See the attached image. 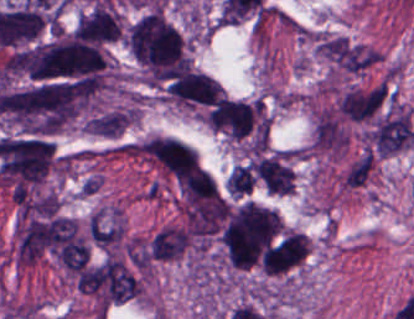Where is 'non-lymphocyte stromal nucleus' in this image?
Here are the masks:
<instances>
[{
    "instance_id": "obj_1",
    "label": "non-lymphocyte stromal nucleus",
    "mask_w": 414,
    "mask_h": 319,
    "mask_svg": "<svg viewBox=\"0 0 414 319\" xmlns=\"http://www.w3.org/2000/svg\"><path fill=\"white\" fill-rule=\"evenodd\" d=\"M391 100L387 82L355 87L340 95L337 111L344 121H369Z\"/></svg>"
},
{
    "instance_id": "obj_5",
    "label": "non-lymphocyte stromal nucleus",
    "mask_w": 414,
    "mask_h": 319,
    "mask_svg": "<svg viewBox=\"0 0 414 319\" xmlns=\"http://www.w3.org/2000/svg\"><path fill=\"white\" fill-rule=\"evenodd\" d=\"M133 118L129 107L103 111L85 123V132L98 137H118L124 132Z\"/></svg>"
},
{
    "instance_id": "obj_2",
    "label": "non-lymphocyte stromal nucleus",
    "mask_w": 414,
    "mask_h": 319,
    "mask_svg": "<svg viewBox=\"0 0 414 319\" xmlns=\"http://www.w3.org/2000/svg\"><path fill=\"white\" fill-rule=\"evenodd\" d=\"M367 135L382 155L396 153L414 142L411 121L404 111L377 120Z\"/></svg>"
},
{
    "instance_id": "obj_6",
    "label": "non-lymphocyte stromal nucleus",
    "mask_w": 414,
    "mask_h": 319,
    "mask_svg": "<svg viewBox=\"0 0 414 319\" xmlns=\"http://www.w3.org/2000/svg\"><path fill=\"white\" fill-rule=\"evenodd\" d=\"M372 160L373 154L366 151L352 162L341 178V185L344 188H358L367 180L372 167Z\"/></svg>"
},
{
    "instance_id": "obj_4",
    "label": "non-lymphocyte stromal nucleus",
    "mask_w": 414,
    "mask_h": 319,
    "mask_svg": "<svg viewBox=\"0 0 414 319\" xmlns=\"http://www.w3.org/2000/svg\"><path fill=\"white\" fill-rule=\"evenodd\" d=\"M187 247V230L179 225H165L150 237L148 255L155 262L172 261L181 256Z\"/></svg>"
},
{
    "instance_id": "obj_3",
    "label": "non-lymphocyte stromal nucleus",
    "mask_w": 414,
    "mask_h": 319,
    "mask_svg": "<svg viewBox=\"0 0 414 319\" xmlns=\"http://www.w3.org/2000/svg\"><path fill=\"white\" fill-rule=\"evenodd\" d=\"M319 45L333 67L357 75L367 69L366 49L335 37H321Z\"/></svg>"
}]
</instances>
